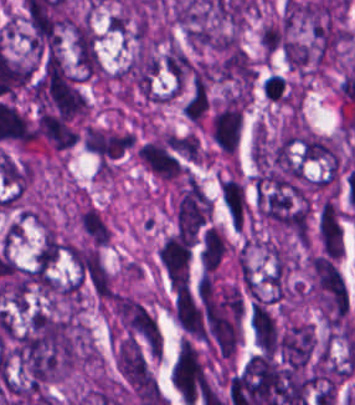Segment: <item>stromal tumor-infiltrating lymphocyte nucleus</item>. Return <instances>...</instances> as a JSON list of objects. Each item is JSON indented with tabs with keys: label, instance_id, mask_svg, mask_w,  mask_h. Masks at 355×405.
<instances>
[{
	"label": "stromal tumor-infiltrating lymphocyte nucleus",
	"instance_id": "stromal-tumor-infiltrating-lymphocyte-nucleus-1",
	"mask_svg": "<svg viewBox=\"0 0 355 405\" xmlns=\"http://www.w3.org/2000/svg\"><path fill=\"white\" fill-rule=\"evenodd\" d=\"M262 93L276 103H288L289 86L283 76L268 72L261 81Z\"/></svg>",
	"mask_w": 355,
	"mask_h": 405
}]
</instances>
